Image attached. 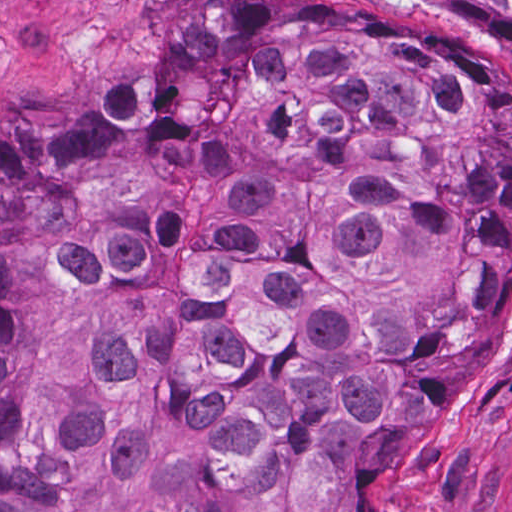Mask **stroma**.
I'll return each instance as SVG.
<instances>
[{"label": "stroma", "instance_id": "35a3bbf8", "mask_svg": "<svg viewBox=\"0 0 512 512\" xmlns=\"http://www.w3.org/2000/svg\"><path fill=\"white\" fill-rule=\"evenodd\" d=\"M223 1L0 0V111H51L94 93L179 8ZM341 2L433 42L485 44L393 0ZM501 50L512 66V52ZM378 512H512V254L499 352L470 380L446 386L401 435Z\"/></svg>", "mask_w": 512, "mask_h": 512}]
</instances>
